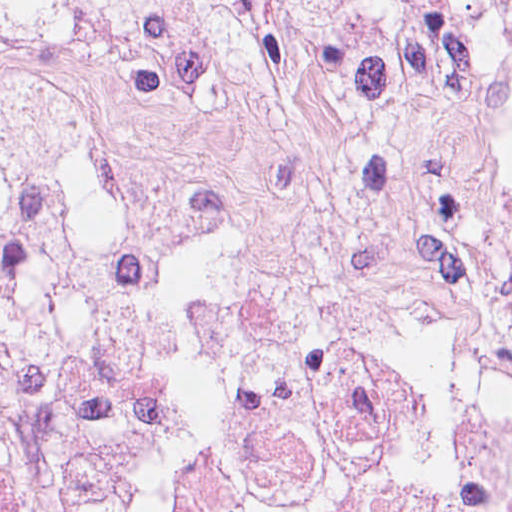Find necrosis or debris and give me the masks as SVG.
<instances>
[{
	"mask_svg": "<svg viewBox=\"0 0 512 512\" xmlns=\"http://www.w3.org/2000/svg\"><path fill=\"white\" fill-rule=\"evenodd\" d=\"M0 453L55 512H512V0H0Z\"/></svg>",
	"mask_w": 512,
	"mask_h": 512,
	"instance_id": "necrosis-or-debris-1",
	"label": "necrosis or debris"
}]
</instances>
